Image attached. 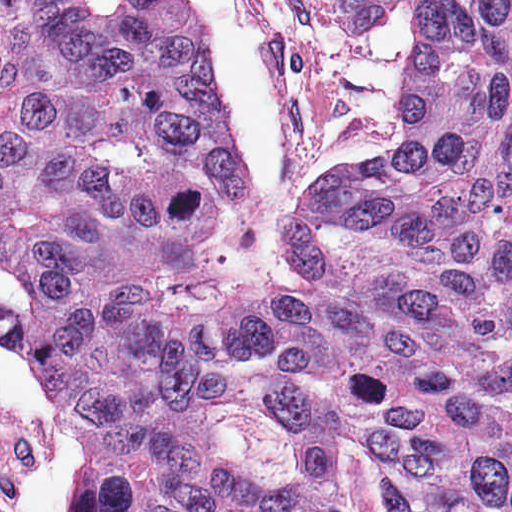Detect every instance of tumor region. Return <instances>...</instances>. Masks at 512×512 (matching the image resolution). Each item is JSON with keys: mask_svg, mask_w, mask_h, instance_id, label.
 Here are the masks:
<instances>
[{"mask_svg": "<svg viewBox=\"0 0 512 512\" xmlns=\"http://www.w3.org/2000/svg\"><path fill=\"white\" fill-rule=\"evenodd\" d=\"M420 9L401 138L279 227L195 0H0V340L83 512H512V0Z\"/></svg>", "mask_w": 512, "mask_h": 512, "instance_id": "e687c5a6", "label": "tumor region"}]
</instances>
